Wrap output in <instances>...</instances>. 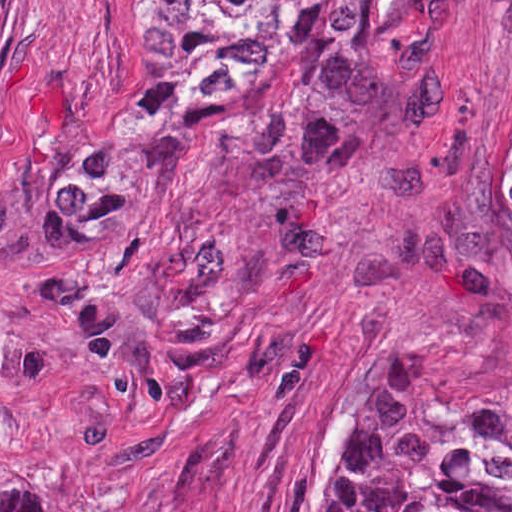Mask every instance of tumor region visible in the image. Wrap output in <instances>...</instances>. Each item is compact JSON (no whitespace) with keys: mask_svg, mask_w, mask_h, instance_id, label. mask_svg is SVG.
<instances>
[{"mask_svg":"<svg viewBox=\"0 0 512 512\" xmlns=\"http://www.w3.org/2000/svg\"><path fill=\"white\" fill-rule=\"evenodd\" d=\"M375 65L354 0H159L146 67L108 142L70 172L39 254L67 312L93 333L94 378L116 411L165 399L228 342L225 289L200 228L146 264L105 253L113 199L167 124L209 116L239 146L319 147ZM505 167L512 184V139ZM0 512L51 511L26 474L0 464ZM323 512H512V399L466 405L441 443L428 424L358 433Z\"/></svg>","mask_w":512,"mask_h":512,"instance_id":"obj_1","label":"tumor region"}]
</instances>
